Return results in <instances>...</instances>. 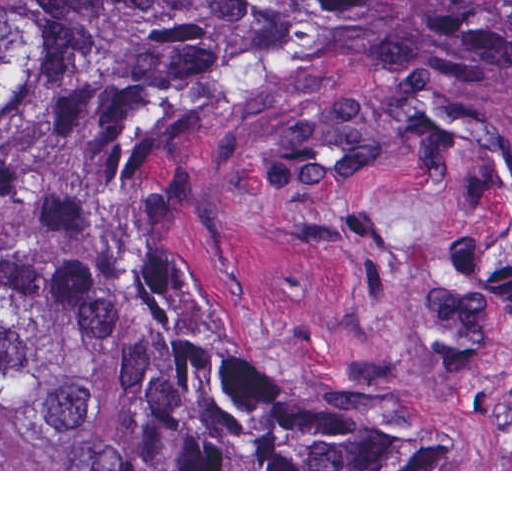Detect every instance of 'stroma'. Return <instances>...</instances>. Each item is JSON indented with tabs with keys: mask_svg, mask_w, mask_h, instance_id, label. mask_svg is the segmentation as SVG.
I'll return each mask as SVG.
<instances>
[{
	"mask_svg": "<svg viewBox=\"0 0 512 512\" xmlns=\"http://www.w3.org/2000/svg\"><path fill=\"white\" fill-rule=\"evenodd\" d=\"M188 209L194 277L253 339L391 410L409 469L0 471H512V325L465 332L450 308L460 254L512 231L494 168L410 159L349 101L259 102L193 145ZM66 238L53 200L0 206V254Z\"/></svg>",
	"mask_w": 512,
	"mask_h": 512,
	"instance_id": "stroma-1",
	"label": "stroma"
}]
</instances>
